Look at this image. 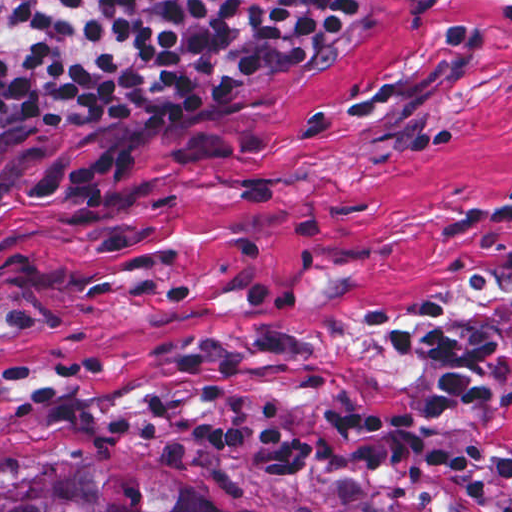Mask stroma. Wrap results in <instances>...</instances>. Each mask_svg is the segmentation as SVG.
Instances as JSON below:
<instances>
[{
  "instance_id": "1",
  "label": "stroma",
  "mask_w": 512,
  "mask_h": 512,
  "mask_svg": "<svg viewBox=\"0 0 512 512\" xmlns=\"http://www.w3.org/2000/svg\"><path fill=\"white\" fill-rule=\"evenodd\" d=\"M316 57L241 94L0 132V460L94 446L216 512H512L463 477L252 473L104 424L312 430L418 411L437 373L383 347L444 309L503 397L437 435L512 458V0H367Z\"/></svg>"
}]
</instances>
